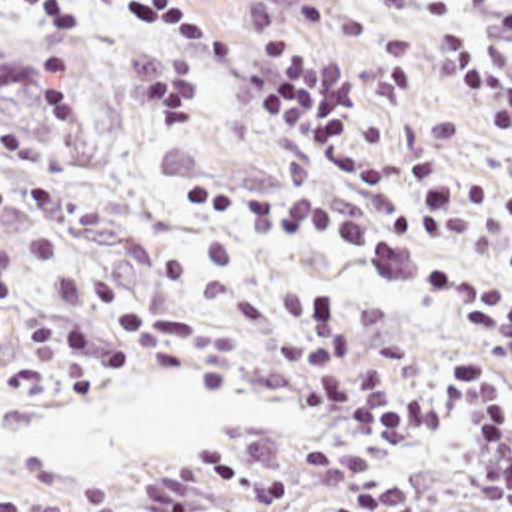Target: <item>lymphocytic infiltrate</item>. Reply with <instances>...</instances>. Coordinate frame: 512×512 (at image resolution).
Here are the masks:
<instances>
[{
  "label": "lymphocytic infiltrate",
  "instance_id": "1",
  "mask_svg": "<svg viewBox=\"0 0 512 512\" xmlns=\"http://www.w3.org/2000/svg\"><path fill=\"white\" fill-rule=\"evenodd\" d=\"M450 0H388L396 15ZM101 0H0L57 49L95 51ZM137 17L165 25L181 47L235 69L259 109L287 127L353 199H382L384 171L347 151V119L361 69L321 57L311 45L261 53L165 0H129ZM450 95L484 121L512 119V63L470 35H438ZM85 71L17 63L0 53V115L41 127L81 85ZM418 237L460 255H492L512 233V195L490 181L454 183L438 155L420 157L406 175ZM179 205L237 229L277 227L329 249H367L359 215L319 195L233 191L183 181ZM512 263V241L504 247ZM21 259L0 243V312L27 334L49 378L99 386L109 374L177 370L193 360L187 340L205 320L125 303L105 283L53 293L59 314L95 316L101 330L23 309ZM446 310L476 330L512 336V287L474 263L430 277ZM261 368L287 404L337 428L305 444L171 452L143 474V512H422L408 492L380 476V460L422 446L464 412L476 422L484 478L496 486V512H512V356L478 340L432 338L412 356L396 354L374 310L343 291L279 287L263 324ZM0 512H41V500L0 486ZM83 512H121L111 488H87Z\"/></svg>",
  "mask_w": 512,
  "mask_h": 512
}]
</instances>
